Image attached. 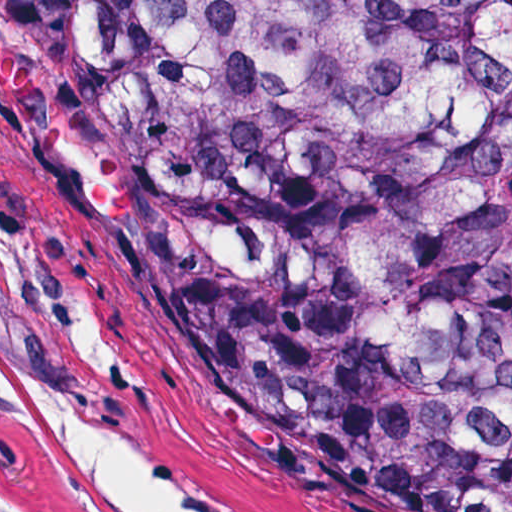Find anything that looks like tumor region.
Instances as JSON below:
<instances>
[{"label": "tumor region", "mask_w": 512, "mask_h": 512, "mask_svg": "<svg viewBox=\"0 0 512 512\" xmlns=\"http://www.w3.org/2000/svg\"><path fill=\"white\" fill-rule=\"evenodd\" d=\"M0 245L512 512V0H0Z\"/></svg>", "instance_id": "1"}]
</instances>
